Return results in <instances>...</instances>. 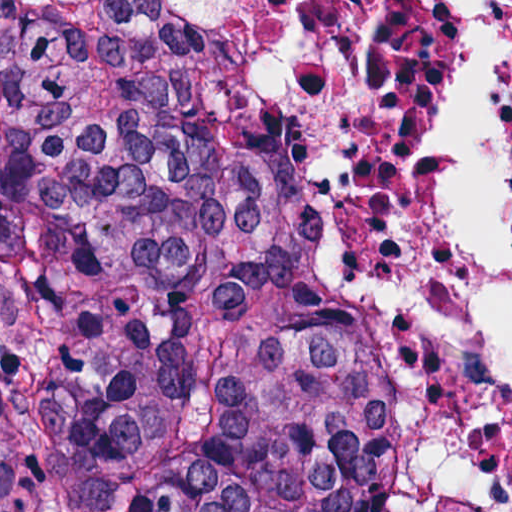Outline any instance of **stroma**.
<instances>
[{
	"label": "stroma",
	"mask_w": 512,
	"mask_h": 512,
	"mask_svg": "<svg viewBox=\"0 0 512 512\" xmlns=\"http://www.w3.org/2000/svg\"><path fill=\"white\" fill-rule=\"evenodd\" d=\"M155 1L244 27L304 58L349 113L354 100L348 67L352 1L512 0H0ZM497 214L512 246V100L497 123Z\"/></svg>",
	"instance_id": "35a3bbf8"
}]
</instances>
